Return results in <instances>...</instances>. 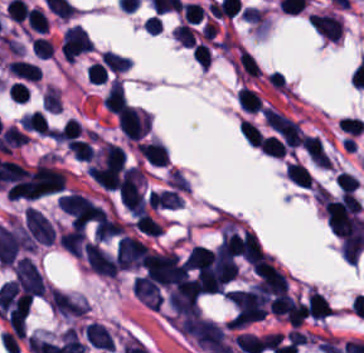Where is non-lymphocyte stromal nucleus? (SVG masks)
Instances as JSON below:
<instances>
[{
    "label": "non-lymphocyte stromal nucleus",
    "mask_w": 364,
    "mask_h": 353,
    "mask_svg": "<svg viewBox=\"0 0 364 353\" xmlns=\"http://www.w3.org/2000/svg\"><path fill=\"white\" fill-rule=\"evenodd\" d=\"M24 227L31 243L52 245L56 240V229L51 222L34 208H27L23 213Z\"/></svg>",
    "instance_id": "dd21d789"
}]
</instances>
